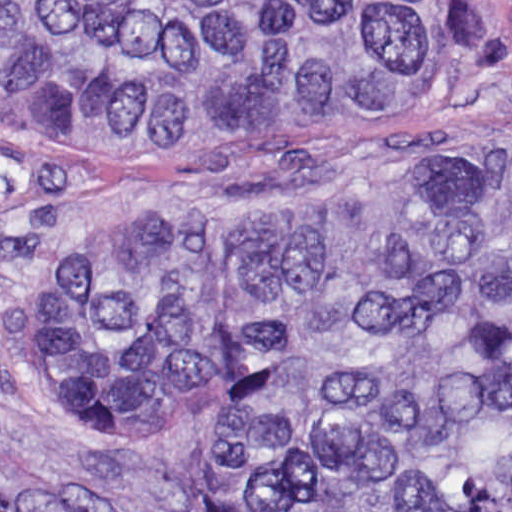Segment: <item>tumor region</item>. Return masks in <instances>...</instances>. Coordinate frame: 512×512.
I'll use <instances>...</instances> for the list:
<instances>
[{"label": "tumor region", "mask_w": 512, "mask_h": 512, "mask_svg": "<svg viewBox=\"0 0 512 512\" xmlns=\"http://www.w3.org/2000/svg\"><path fill=\"white\" fill-rule=\"evenodd\" d=\"M465 0H0V129L245 144L488 71ZM31 347L75 440L213 420V512H512V144L258 213H103Z\"/></svg>", "instance_id": "tumor-region-1"}]
</instances>
